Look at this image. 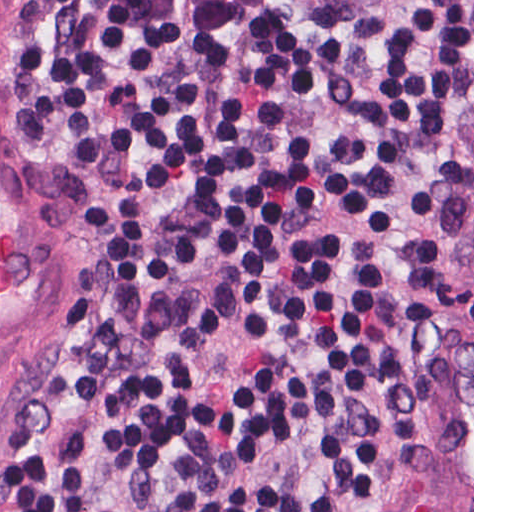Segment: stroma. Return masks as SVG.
Masks as SVG:
<instances>
[{"instance_id":"obj_1","label":"stroma","mask_w":512,"mask_h":512,"mask_svg":"<svg viewBox=\"0 0 512 512\" xmlns=\"http://www.w3.org/2000/svg\"><path fill=\"white\" fill-rule=\"evenodd\" d=\"M45 0H0V512L88 317L104 250L90 171L32 143ZM360 512H474V0H472V419L373 461Z\"/></svg>"}]
</instances>
